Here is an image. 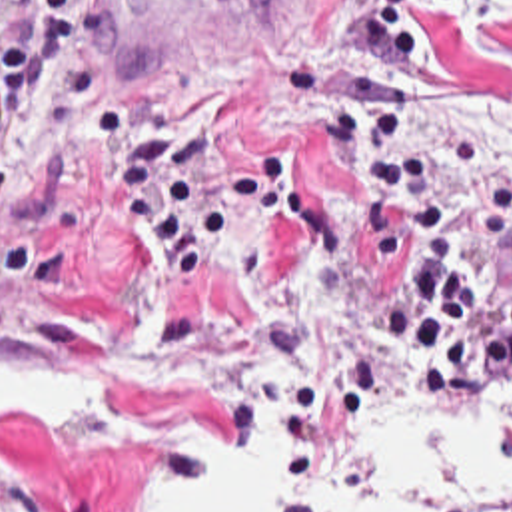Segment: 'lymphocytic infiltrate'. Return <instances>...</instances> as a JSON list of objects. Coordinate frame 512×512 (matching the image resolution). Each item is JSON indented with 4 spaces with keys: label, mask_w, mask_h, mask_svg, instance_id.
Listing matches in <instances>:
<instances>
[{
    "label": "lymphocytic infiltrate",
    "mask_w": 512,
    "mask_h": 512,
    "mask_svg": "<svg viewBox=\"0 0 512 512\" xmlns=\"http://www.w3.org/2000/svg\"><path fill=\"white\" fill-rule=\"evenodd\" d=\"M80 5L0 0V141L14 137L28 103L60 111L100 153L121 211L181 287L195 291L241 233L291 211V163L219 153L203 133L171 131L125 109L108 85L78 93L68 21ZM331 155L369 187V273L401 277L381 341L409 391L465 409L491 371L512 367V283H469L443 175L407 145L381 91H351L335 111Z\"/></svg>",
    "instance_id": "lymphocytic-infiltrate-1"
}]
</instances>
